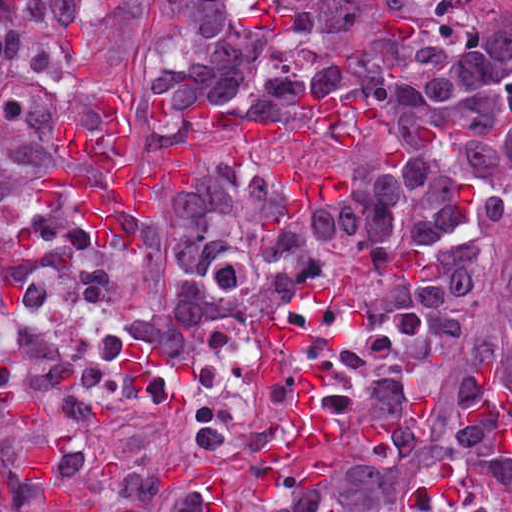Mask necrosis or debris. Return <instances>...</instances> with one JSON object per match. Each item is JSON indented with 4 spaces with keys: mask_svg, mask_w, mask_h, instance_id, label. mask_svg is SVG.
I'll use <instances>...</instances> for the list:
<instances>
[{
    "mask_svg": "<svg viewBox=\"0 0 512 512\" xmlns=\"http://www.w3.org/2000/svg\"><path fill=\"white\" fill-rule=\"evenodd\" d=\"M319 275H301L266 315H227L205 343L149 356L130 334L109 290L60 272H36L20 303L0 312V367L51 343H73L76 380L106 400L157 408L351 321Z\"/></svg>",
    "mask_w": 512,
    "mask_h": 512,
    "instance_id": "1",
    "label": "necrosis or debris"
}]
</instances>
